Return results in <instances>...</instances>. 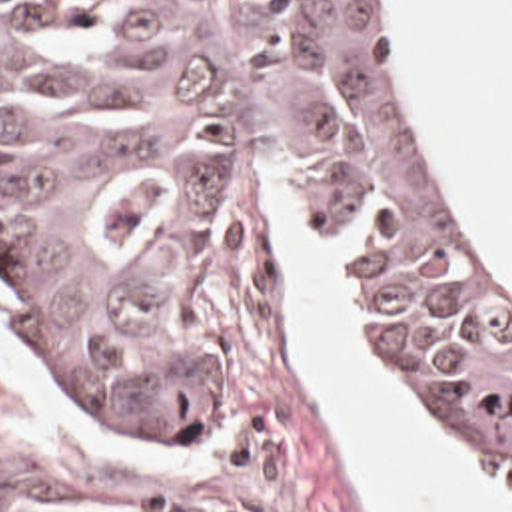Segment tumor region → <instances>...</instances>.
Listing matches in <instances>:
<instances>
[{
    "label": "tumor region",
    "mask_w": 512,
    "mask_h": 512,
    "mask_svg": "<svg viewBox=\"0 0 512 512\" xmlns=\"http://www.w3.org/2000/svg\"><path fill=\"white\" fill-rule=\"evenodd\" d=\"M257 147L359 243L403 373L512 478V277L418 133L381 0H239L195 47L0 0V263L59 379L139 444L219 440L199 303Z\"/></svg>",
    "instance_id": "e687c5a6"
}]
</instances>
